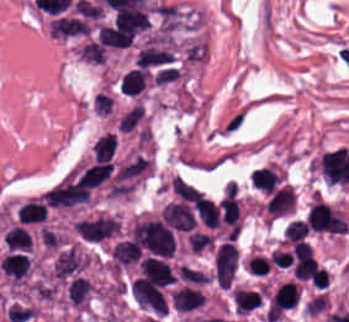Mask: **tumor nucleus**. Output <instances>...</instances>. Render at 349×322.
I'll return each instance as SVG.
<instances>
[{"label":"tumor nucleus","instance_id":"tumor-nucleus-1","mask_svg":"<svg viewBox=\"0 0 349 322\" xmlns=\"http://www.w3.org/2000/svg\"><path fill=\"white\" fill-rule=\"evenodd\" d=\"M240 252L235 242L222 243L214 254L213 278L219 287L229 289L233 283Z\"/></svg>","mask_w":349,"mask_h":322},{"label":"tumor nucleus","instance_id":"tumor-nucleus-2","mask_svg":"<svg viewBox=\"0 0 349 322\" xmlns=\"http://www.w3.org/2000/svg\"><path fill=\"white\" fill-rule=\"evenodd\" d=\"M301 285L297 280H277L267 291V304L271 311L294 308L299 302Z\"/></svg>","mask_w":349,"mask_h":322},{"label":"tumor nucleus","instance_id":"tumor-nucleus-3","mask_svg":"<svg viewBox=\"0 0 349 322\" xmlns=\"http://www.w3.org/2000/svg\"><path fill=\"white\" fill-rule=\"evenodd\" d=\"M287 174L288 172L283 165L270 160L254 169L251 182L255 187L268 194L285 184Z\"/></svg>","mask_w":349,"mask_h":322},{"label":"tumor nucleus","instance_id":"tumor-nucleus-4","mask_svg":"<svg viewBox=\"0 0 349 322\" xmlns=\"http://www.w3.org/2000/svg\"><path fill=\"white\" fill-rule=\"evenodd\" d=\"M151 84V71L144 67H130L119 79V89L131 96H146Z\"/></svg>","mask_w":349,"mask_h":322},{"label":"tumor nucleus","instance_id":"tumor-nucleus-5","mask_svg":"<svg viewBox=\"0 0 349 322\" xmlns=\"http://www.w3.org/2000/svg\"><path fill=\"white\" fill-rule=\"evenodd\" d=\"M230 293L236 314H248L263 302L262 290L243 284H236Z\"/></svg>","mask_w":349,"mask_h":322},{"label":"tumor nucleus","instance_id":"tumor-nucleus-6","mask_svg":"<svg viewBox=\"0 0 349 322\" xmlns=\"http://www.w3.org/2000/svg\"><path fill=\"white\" fill-rule=\"evenodd\" d=\"M116 133L114 131H106L91 144L92 155L97 160H110L115 153Z\"/></svg>","mask_w":349,"mask_h":322},{"label":"tumor nucleus","instance_id":"tumor-nucleus-7","mask_svg":"<svg viewBox=\"0 0 349 322\" xmlns=\"http://www.w3.org/2000/svg\"><path fill=\"white\" fill-rule=\"evenodd\" d=\"M308 235L309 232L305 220L293 218L283 233V239L286 243H295L308 237Z\"/></svg>","mask_w":349,"mask_h":322}]
</instances>
